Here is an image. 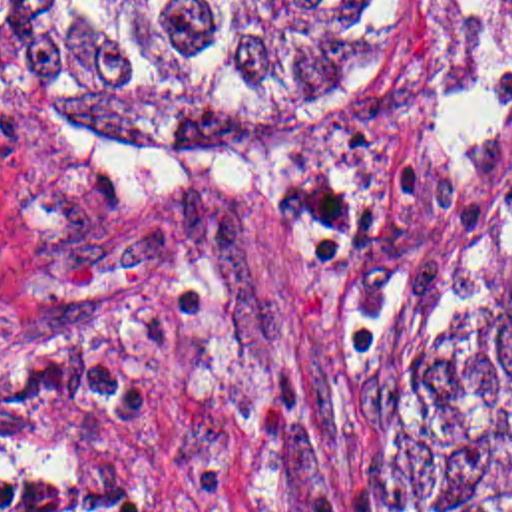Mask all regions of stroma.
Segmentation results:
<instances>
[{
    "label": "stroma",
    "mask_w": 512,
    "mask_h": 512,
    "mask_svg": "<svg viewBox=\"0 0 512 512\" xmlns=\"http://www.w3.org/2000/svg\"><path fill=\"white\" fill-rule=\"evenodd\" d=\"M512 251V0H415L397 105L206 153L0 81V448L112 512H371L377 420Z\"/></svg>",
    "instance_id": "stroma-1"
}]
</instances>
